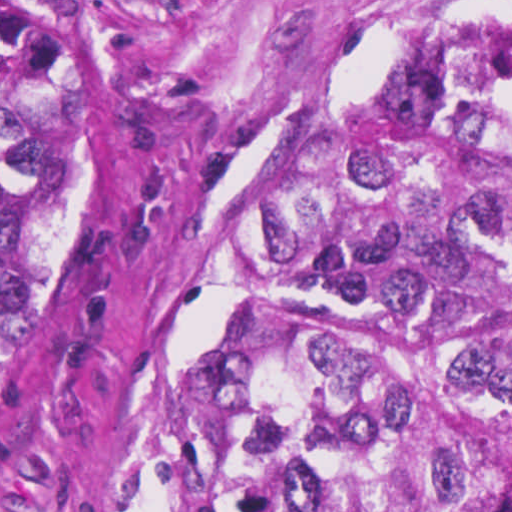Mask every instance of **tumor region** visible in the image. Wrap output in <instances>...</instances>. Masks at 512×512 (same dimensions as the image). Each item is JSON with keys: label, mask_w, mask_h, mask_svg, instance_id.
Segmentation results:
<instances>
[{"label": "tumor region", "mask_w": 512, "mask_h": 512, "mask_svg": "<svg viewBox=\"0 0 512 512\" xmlns=\"http://www.w3.org/2000/svg\"><path fill=\"white\" fill-rule=\"evenodd\" d=\"M0 1V410L89 236V124ZM266 298L150 380L145 512H453L444 341L512 404V6L423 29L295 159ZM411 321L390 323L389 311Z\"/></svg>", "instance_id": "tumor-region-1"}]
</instances>
